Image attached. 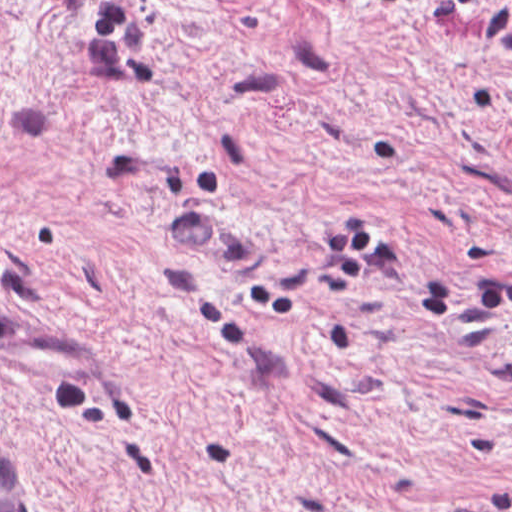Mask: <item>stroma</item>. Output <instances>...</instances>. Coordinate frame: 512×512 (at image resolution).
Masks as SVG:
<instances>
[{
    "label": "stroma",
    "instance_id": "35a3bbf8",
    "mask_svg": "<svg viewBox=\"0 0 512 512\" xmlns=\"http://www.w3.org/2000/svg\"><path fill=\"white\" fill-rule=\"evenodd\" d=\"M0 435L35 512H512V0H0Z\"/></svg>",
    "mask_w": 512,
    "mask_h": 512
}]
</instances>
